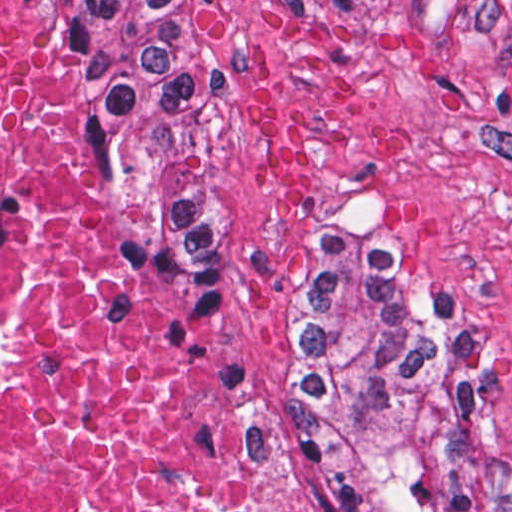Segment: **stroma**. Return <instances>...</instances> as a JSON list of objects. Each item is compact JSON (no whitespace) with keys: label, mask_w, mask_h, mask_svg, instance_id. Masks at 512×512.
I'll list each match as a JSON object with an SVG mask.
<instances>
[{"label":"stroma","mask_w":512,"mask_h":512,"mask_svg":"<svg viewBox=\"0 0 512 512\" xmlns=\"http://www.w3.org/2000/svg\"><path fill=\"white\" fill-rule=\"evenodd\" d=\"M217 80L206 110L201 258L212 317L251 402L288 377V340L316 222L339 200L382 238L394 300L476 369L492 478L478 512H512V0H215ZM91 134L114 243L137 294L210 363L293 512L292 464L267 446L228 363L166 289Z\"/></svg>","instance_id":"stroma-1"}]
</instances>
